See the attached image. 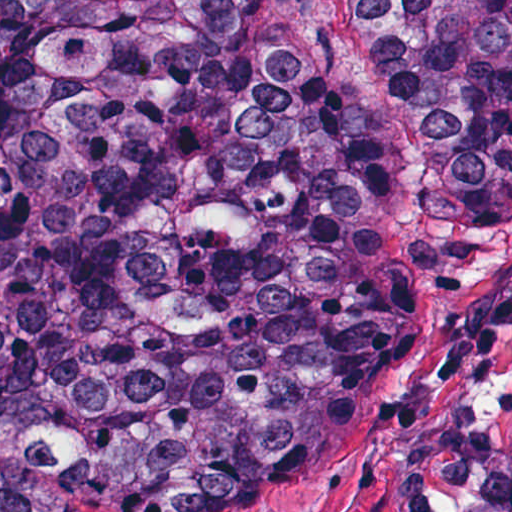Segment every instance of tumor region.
<instances>
[{
    "instance_id": "1",
    "label": "tumor region",
    "mask_w": 512,
    "mask_h": 512,
    "mask_svg": "<svg viewBox=\"0 0 512 512\" xmlns=\"http://www.w3.org/2000/svg\"><path fill=\"white\" fill-rule=\"evenodd\" d=\"M349 20L434 213L512 177V0ZM417 318L400 171L315 0H0V512L340 462Z\"/></svg>"
}]
</instances>
